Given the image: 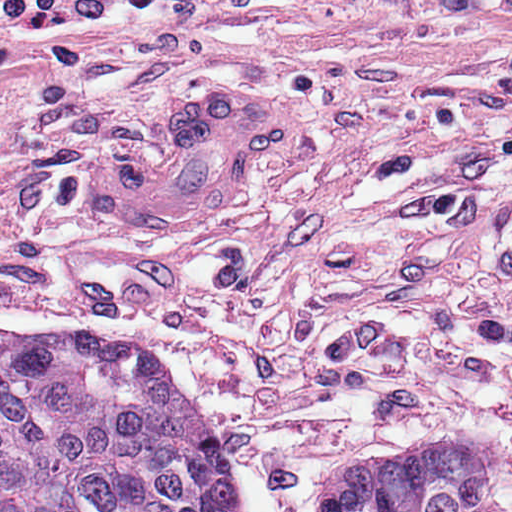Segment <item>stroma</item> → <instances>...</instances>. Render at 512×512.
Segmentation results:
<instances>
[{
    "instance_id": "stroma-1",
    "label": "stroma",
    "mask_w": 512,
    "mask_h": 512,
    "mask_svg": "<svg viewBox=\"0 0 512 512\" xmlns=\"http://www.w3.org/2000/svg\"><path fill=\"white\" fill-rule=\"evenodd\" d=\"M296 140L195 234L109 224L87 145L202 93ZM0 329L158 349L251 512L389 447L486 458L512 512V0H168L0 64Z\"/></svg>"
}]
</instances>
